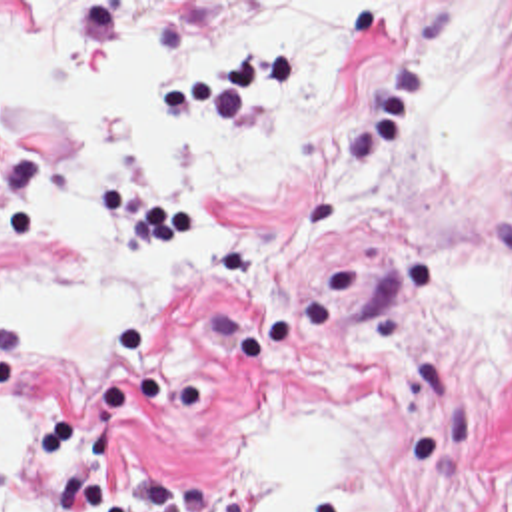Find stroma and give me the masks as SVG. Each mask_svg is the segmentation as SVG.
Instances as JSON below:
<instances>
[{
  "label": "stroma",
  "mask_w": 512,
  "mask_h": 512,
  "mask_svg": "<svg viewBox=\"0 0 512 512\" xmlns=\"http://www.w3.org/2000/svg\"><path fill=\"white\" fill-rule=\"evenodd\" d=\"M22 24L108 40L188 38L282 2H348L368 44L338 66L328 118L296 132L274 184L222 188L246 250L200 258L152 317L120 315L84 367L44 365L48 417L22 455L20 512H204L256 425L310 403L376 453L348 512H512V343L486 353L454 276L512 278V58L486 100L480 178L412 148L406 120L462 78L444 2L0 0ZM78 152L0 122V288L106 270L90 238L24 244ZM16 379L0 333V393Z\"/></svg>",
  "instance_id": "stroma-1"
}]
</instances>
